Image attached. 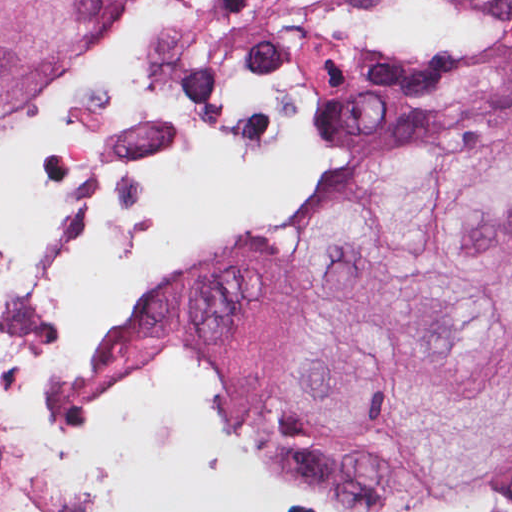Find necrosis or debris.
<instances>
[{
  "label": "necrosis or debris",
  "mask_w": 512,
  "mask_h": 512,
  "mask_svg": "<svg viewBox=\"0 0 512 512\" xmlns=\"http://www.w3.org/2000/svg\"><path fill=\"white\" fill-rule=\"evenodd\" d=\"M368 0H120L0 133V358L55 318L110 218L247 146L377 41Z\"/></svg>",
  "instance_id": "obj_1"
}]
</instances>
